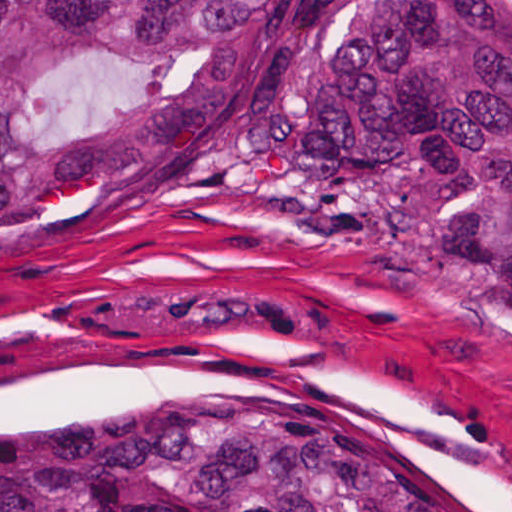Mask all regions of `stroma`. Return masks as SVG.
I'll list each match as a JSON object with an SVG mask.
<instances>
[{
  "label": "stroma",
  "instance_id": "stroma-1",
  "mask_svg": "<svg viewBox=\"0 0 512 512\" xmlns=\"http://www.w3.org/2000/svg\"><path fill=\"white\" fill-rule=\"evenodd\" d=\"M261 391H335L415 472L512 512V322L462 290L130 164L0 192V419Z\"/></svg>",
  "mask_w": 512,
  "mask_h": 512
}]
</instances>
